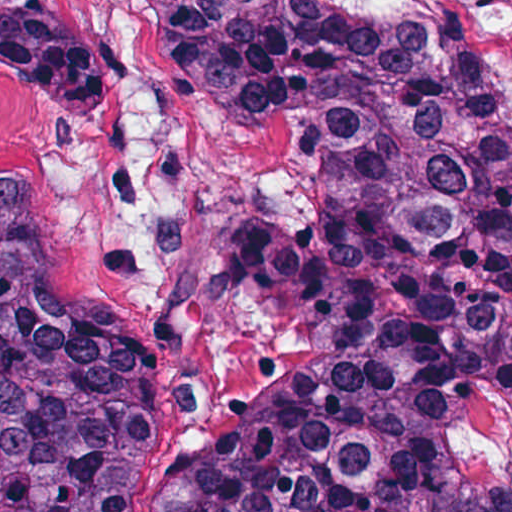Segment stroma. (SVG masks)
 Instances as JSON below:
<instances>
[{
  "label": "stroma",
  "instance_id": "1",
  "mask_svg": "<svg viewBox=\"0 0 512 512\" xmlns=\"http://www.w3.org/2000/svg\"><path fill=\"white\" fill-rule=\"evenodd\" d=\"M119 72L105 110L0 76V172L28 196L53 280L138 354L126 512H168L211 442L272 405L239 242L257 210L314 217L284 136L189 92L122 0H52Z\"/></svg>",
  "mask_w": 512,
  "mask_h": 512
}]
</instances>
